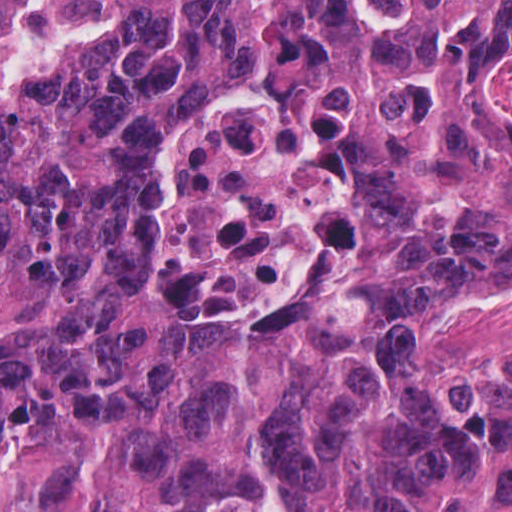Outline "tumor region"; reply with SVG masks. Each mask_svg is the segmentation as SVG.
I'll list each match as a JSON object with an SVG mask.
<instances>
[{
  "mask_svg": "<svg viewBox=\"0 0 512 512\" xmlns=\"http://www.w3.org/2000/svg\"><path fill=\"white\" fill-rule=\"evenodd\" d=\"M512 0H0V512H512ZM260 91L335 162L293 292L173 318L158 160Z\"/></svg>",
  "mask_w": 512,
  "mask_h": 512,
  "instance_id": "obj_1",
  "label": "tumor region"
}]
</instances>
